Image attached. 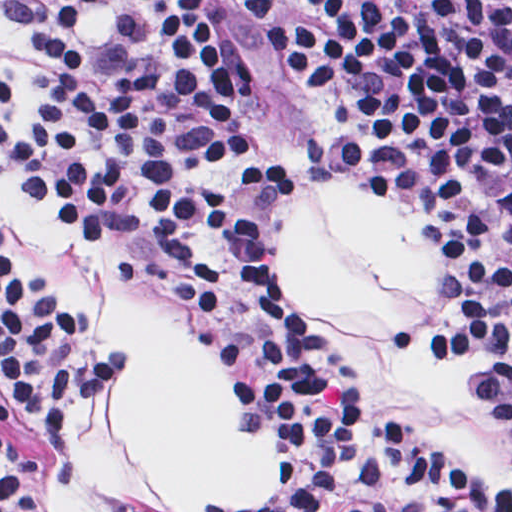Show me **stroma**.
<instances>
[{
    "label": "stroma",
    "instance_id": "35a3bbf8",
    "mask_svg": "<svg viewBox=\"0 0 512 512\" xmlns=\"http://www.w3.org/2000/svg\"><path fill=\"white\" fill-rule=\"evenodd\" d=\"M98 0H67L50 11H29L22 0H0V220L20 255L84 336L102 353L104 385L86 425L65 429L35 408L15 387L0 362V425L43 470L25 456L9 465L30 494L36 512H175L166 485L137 444L130 425L133 376L126 356L95 330L100 304L114 287L138 295L180 341L209 346L153 293L86 259L56 225L16 173L5 151L2 127L22 63L33 49H111L132 42L144 23L142 0L111 2V35L86 41L76 16ZM239 41L241 67L257 102L276 130L280 155L268 173V236L279 217L316 184L361 180L412 225L432 235L460 266L457 292L448 283L433 320L389 324L399 344H421L462 359L481 372V412L507 437L499 416V387L484 342L455 311L472 298L477 274L464 232L412 176H334L311 172L302 150L316 133L309 114L288 88L236 0H197ZM268 267L290 303L347 359L383 431L423 467L469 494L512 512V480H472L435 442L377 406L364 382L360 360L345 350L333 328L317 317L305 296L282 279L268 239ZM226 359V358H225ZM227 360V359H226ZM230 364L234 431L277 427V472L259 489L216 500L202 512H303L307 455L278 423L259 416L252 376Z\"/></svg>",
    "mask_w": 512,
    "mask_h": 512
}]
</instances>
